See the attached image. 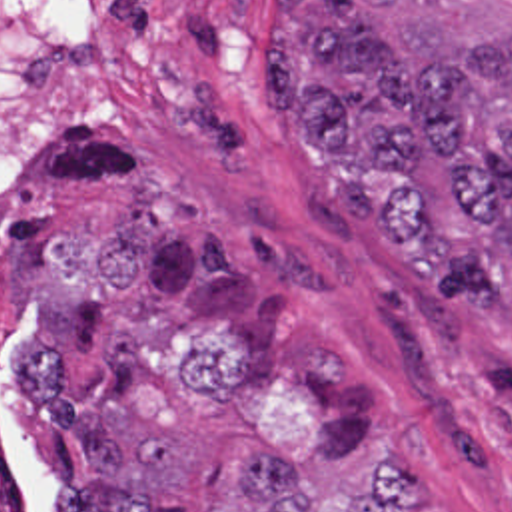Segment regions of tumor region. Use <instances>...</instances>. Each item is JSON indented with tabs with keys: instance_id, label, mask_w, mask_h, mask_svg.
Instances as JSON below:
<instances>
[{
	"instance_id": "tumor-region-1",
	"label": "tumor region",
	"mask_w": 512,
	"mask_h": 512,
	"mask_svg": "<svg viewBox=\"0 0 512 512\" xmlns=\"http://www.w3.org/2000/svg\"><path fill=\"white\" fill-rule=\"evenodd\" d=\"M262 94L330 168L398 180L384 236L450 304H512V0H276ZM14 419L52 512H444L338 337L210 290L188 220L122 206L28 266Z\"/></svg>"
}]
</instances>
